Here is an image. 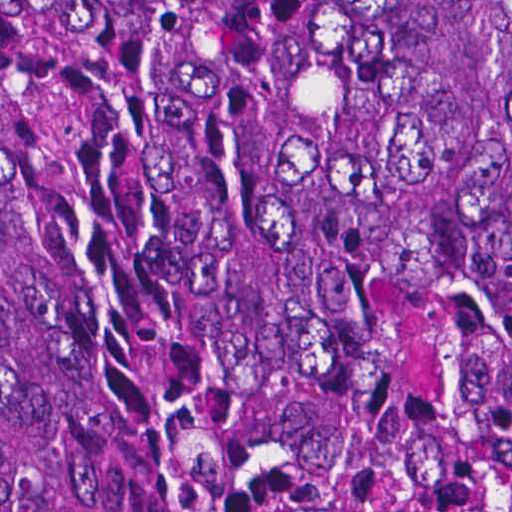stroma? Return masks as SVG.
<instances>
[{
	"label": "stroma",
	"instance_id": "stroma-1",
	"mask_svg": "<svg viewBox=\"0 0 512 512\" xmlns=\"http://www.w3.org/2000/svg\"><path fill=\"white\" fill-rule=\"evenodd\" d=\"M374 297V345L376 351V307ZM457 306L463 329V357L472 406L487 437L512 479V453L496 414L480 304L450 297Z\"/></svg>",
	"mask_w": 512,
	"mask_h": 512
}]
</instances>
